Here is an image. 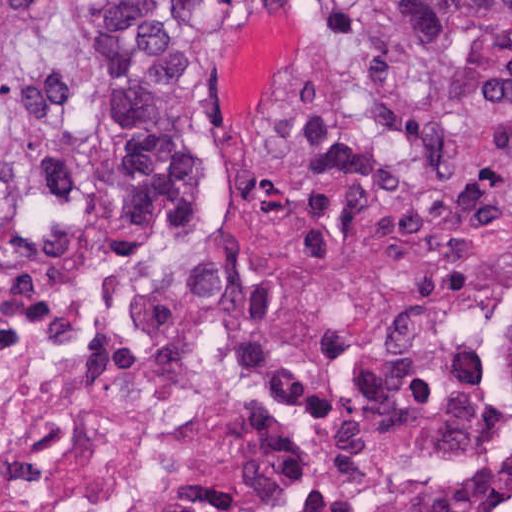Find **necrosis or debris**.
Wrapping results in <instances>:
<instances>
[{
	"instance_id": "obj_1",
	"label": "necrosis or debris",
	"mask_w": 512,
	"mask_h": 512,
	"mask_svg": "<svg viewBox=\"0 0 512 512\" xmlns=\"http://www.w3.org/2000/svg\"><path fill=\"white\" fill-rule=\"evenodd\" d=\"M512 230L242 289L0 186V512H512Z\"/></svg>"
}]
</instances>
